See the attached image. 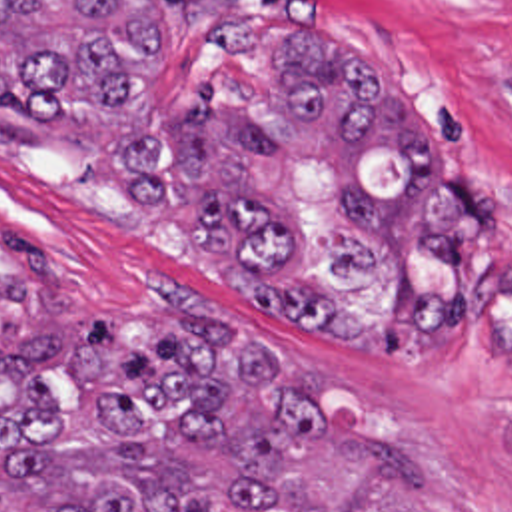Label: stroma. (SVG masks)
Wrapping results in <instances>:
<instances>
[{
  "mask_svg": "<svg viewBox=\"0 0 512 512\" xmlns=\"http://www.w3.org/2000/svg\"><path fill=\"white\" fill-rule=\"evenodd\" d=\"M162 81L116 117L60 119L46 145L0 143V279L28 277L76 331H124L172 295L260 323L320 377L322 395L414 452L440 512H512V0H140ZM308 27L374 61L426 111L456 183L484 197V245L466 263L472 321L456 341L336 343L248 307L234 271L188 243L182 203L142 207L118 147L216 85L242 115L272 117L280 47ZM422 107H420V103ZM48 297V299H46Z\"/></svg>",
  "mask_w": 512,
  "mask_h": 512,
  "instance_id": "1",
  "label": "stroma"
}]
</instances>
